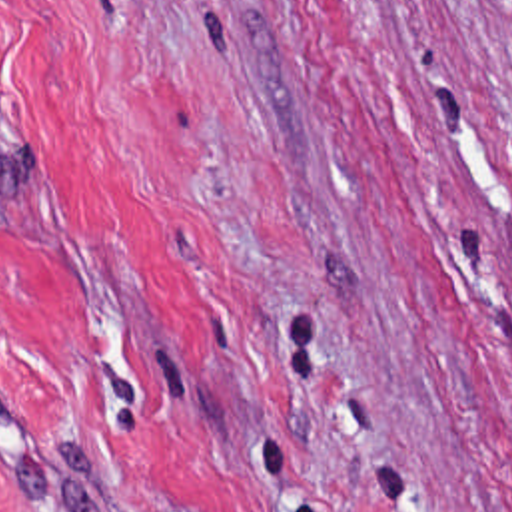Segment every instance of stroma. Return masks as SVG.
<instances>
[{
    "mask_svg": "<svg viewBox=\"0 0 512 512\" xmlns=\"http://www.w3.org/2000/svg\"><path fill=\"white\" fill-rule=\"evenodd\" d=\"M0 512H512V0H0Z\"/></svg>",
    "mask_w": 512,
    "mask_h": 512,
    "instance_id": "1",
    "label": "stroma"
}]
</instances>
